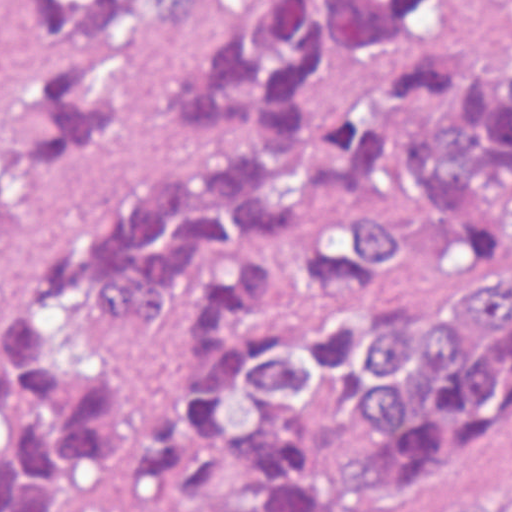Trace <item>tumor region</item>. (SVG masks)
<instances>
[{"label": "tumor region", "mask_w": 512, "mask_h": 512, "mask_svg": "<svg viewBox=\"0 0 512 512\" xmlns=\"http://www.w3.org/2000/svg\"><path fill=\"white\" fill-rule=\"evenodd\" d=\"M272 289L251 264L191 298L188 358L134 447L157 496L204 502L223 473L256 462L237 488L245 512H332L348 486L446 465L512 415V298L236 323ZM457 512L498 511L466 493Z\"/></svg>", "instance_id": "1"}]
</instances>
